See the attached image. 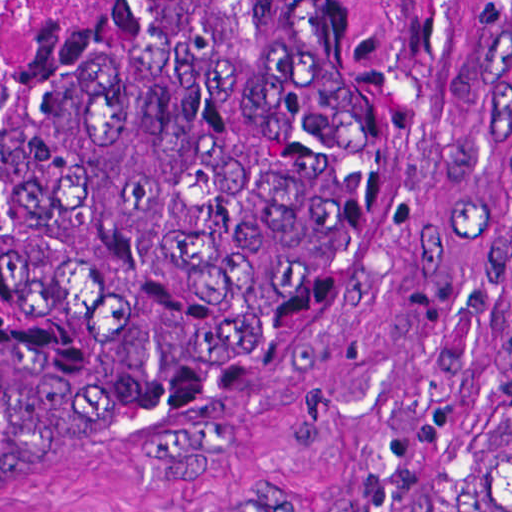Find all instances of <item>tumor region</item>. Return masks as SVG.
<instances>
[{"instance_id":"tumor-region-1","label":"tumor region","mask_w":512,"mask_h":512,"mask_svg":"<svg viewBox=\"0 0 512 512\" xmlns=\"http://www.w3.org/2000/svg\"><path fill=\"white\" fill-rule=\"evenodd\" d=\"M505 0H61L0 92V500L298 353L454 159ZM447 512H512V388Z\"/></svg>"}]
</instances>
